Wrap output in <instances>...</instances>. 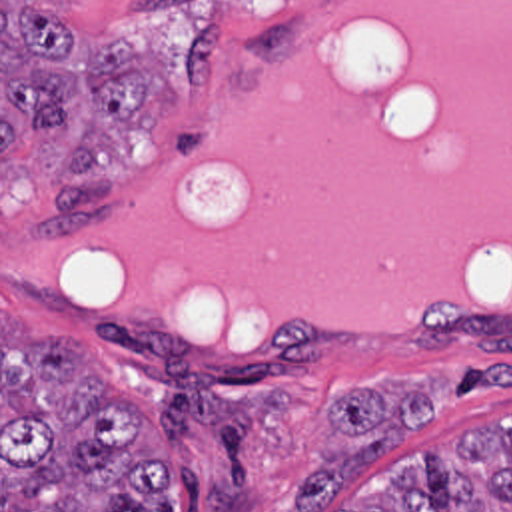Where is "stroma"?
<instances>
[{"mask_svg": "<svg viewBox=\"0 0 512 512\" xmlns=\"http://www.w3.org/2000/svg\"><path fill=\"white\" fill-rule=\"evenodd\" d=\"M317 0H0V512H2V312L36 344L70 342L106 387L138 409L150 429L180 453V512H292V489L321 461L363 443L335 421L331 405L375 387L391 399L417 393L429 417L389 447L381 461L331 495L325 512H357L385 501L423 461L475 437L512 435V314L431 310L405 342L349 340L288 326L264 348L172 338L80 310L28 284L2 282V210L54 208L64 128L2 158V6L62 8L70 48H94L92 32L136 46L160 72V118L102 168L116 192L112 224L60 244H94L134 222L140 182L214 124V90L242 54L276 52Z\"/></svg>", "mask_w": 512, "mask_h": 512, "instance_id": "1", "label": "stroma"}]
</instances>
